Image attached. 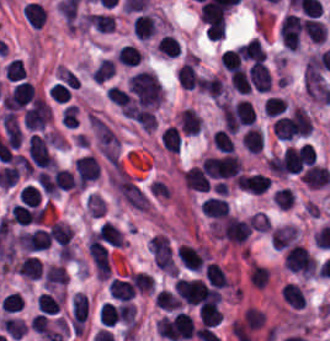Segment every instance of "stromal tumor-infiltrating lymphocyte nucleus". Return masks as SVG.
Masks as SVG:
<instances>
[{
	"label": "stromal tumor-infiltrating lymphocyte nucleus",
	"instance_id": "stromal-tumor-infiltrating-lymphocyte-nucleus-1",
	"mask_svg": "<svg viewBox=\"0 0 330 341\" xmlns=\"http://www.w3.org/2000/svg\"><path fill=\"white\" fill-rule=\"evenodd\" d=\"M284 266L293 273L310 277L316 273V261L304 245L293 244L284 253Z\"/></svg>",
	"mask_w": 330,
	"mask_h": 341
},
{
	"label": "stromal tumor-infiltrating lymphocyte nucleus",
	"instance_id": "stromal-tumor-infiltrating-lymphocyte-nucleus-2",
	"mask_svg": "<svg viewBox=\"0 0 330 341\" xmlns=\"http://www.w3.org/2000/svg\"><path fill=\"white\" fill-rule=\"evenodd\" d=\"M173 289L185 305H199L207 297V287L200 279L178 278Z\"/></svg>",
	"mask_w": 330,
	"mask_h": 341
},
{
	"label": "stromal tumor-infiltrating lymphocyte nucleus",
	"instance_id": "stromal-tumor-infiltrating-lymphocyte-nucleus-3",
	"mask_svg": "<svg viewBox=\"0 0 330 341\" xmlns=\"http://www.w3.org/2000/svg\"><path fill=\"white\" fill-rule=\"evenodd\" d=\"M35 98L33 85L30 81L20 80L3 97L2 105L7 110H19Z\"/></svg>",
	"mask_w": 330,
	"mask_h": 341
},
{
	"label": "stromal tumor-infiltrating lymphocyte nucleus",
	"instance_id": "stromal-tumor-infiltrating-lymphocyte-nucleus-4",
	"mask_svg": "<svg viewBox=\"0 0 330 341\" xmlns=\"http://www.w3.org/2000/svg\"><path fill=\"white\" fill-rule=\"evenodd\" d=\"M236 184L248 193L263 194L270 185V178L262 172L245 173L236 177Z\"/></svg>",
	"mask_w": 330,
	"mask_h": 341
},
{
	"label": "stromal tumor-infiltrating lymphocyte nucleus",
	"instance_id": "stromal-tumor-infiltrating-lymphocyte-nucleus-5",
	"mask_svg": "<svg viewBox=\"0 0 330 341\" xmlns=\"http://www.w3.org/2000/svg\"><path fill=\"white\" fill-rule=\"evenodd\" d=\"M183 182L187 189L199 192H209L211 186L209 176L199 166H192L183 172Z\"/></svg>",
	"mask_w": 330,
	"mask_h": 341
},
{
	"label": "stromal tumor-infiltrating lymphocyte nucleus",
	"instance_id": "stromal-tumor-infiltrating-lymphocyte-nucleus-6",
	"mask_svg": "<svg viewBox=\"0 0 330 341\" xmlns=\"http://www.w3.org/2000/svg\"><path fill=\"white\" fill-rule=\"evenodd\" d=\"M246 75L250 87L256 92H269L270 76L263 64L252 62Z\"/></svg>",
	"mask_w": 330,
	"mask_h": 341
},
{
	"label": "stromal tumor-infiltrating lymphocyte nucleus",
	"instance_id": "stromal-tumor-infiltrating-lymphocyte-nucleus-7",
	"mask_svg": "<svg viewBox=\"0 0 330 341\" xmlns=\"http://www.w3.org/2000/svg\"><path fill=\"white\" fill-rule=\"evenodd\" d=\"M200 321L206 327H216L221 324L223 312L219 299H211L199 308Z\"/></svg>",
	"mask_w": 330,
	"mask_h": 341
},
{
	"label": "stromal tumor-infiltrating lymphocyte nucleus",
	"instance_id": "stromal-tumor-infiltrating-lymphocyte-nucleus-8",
	"mask_svg": "<svg viewBox=\"0 0 330 341\" xmlns=\"http://www.w3.org/2000/svg\"><path fill=\"white\" fill-rule=\"evenodd\" d=\"M301 181L309 188H322L330 184V173L325 167L314 163L303 172Z\"/></svg>",
	"mask_w": 330,
	"mask_h": 341
},
{
	"label": "stromal tumor-infiltrating lymphocyte nucleus",
	"instance_id": "stromal-tumor-infiltrating-lymphocyte-nucleus-9",
	"mask_svg": "<svg viewBox=\"0 0 330 341\" xmlns=\"http://www.w3.org/2000/svg\"><path fill=\"white\" fill-rule=\"evenodd\" d=\"M230 207L221 197H208L200 204V211L206 218L226 219Z\"/></svg>",
	"mask_w": 330,
	"mask_h": 341
},
{
	"label": "stromal tumor-infiltrating lymphocyte nucleus",
	"instance_id": "stromal-tumor-infiltrating-lymphocyte-nucleus-10",
	"mask_svg": "<svg viewBox=\"0 0 330 341\" xmlns=\"http://www.w3.org/2000/svg\"><path fill=\"white\" fill-rule=\"evenodd\" d=\"M179 86L193 90L198 82L197 66L194 59H187L179 67L176 75Z\"/></svg>",
	"mask_w": 330,
	"mask_h": 341
},
{
	"label": "stromal tumor-infiltrating lymphocyte nucleus",
	"instance_id": "stromal-tumor-infiltrating-lymphocyte-nucleus-11",
	"mask_svg": "<svg viewBox=\"0 0 330 341\" xmlns=\"http://www.w3.org/2000/svg\"><path fill=\"white\" fill-rule=\"evenodd\" d=\"M15 268L20 276L29 280H37L43 274V263L35 255H27Z\"/></svg>",
	"mask_w": 330,
	"mask_h": 341
},
{
	"label": "stromal tumor-infiltrating lymphocyte nucleus",
	"instance_id": "stromal-tumor-infiltrating-lymphocyte-nucleus-12",
	"mask_svg": "<svg viewBox=\"0 0 330 341\" xmlns=\"http://www.w3.org/2000/svg\"><path fill=\"white\" fill-rule=\"evenodd\" d=\"M237 48L245 61L264 63L267 57L260 40L256 36Z\"/></svg>",
	"mask_w": 330,
	"mask_h": 341
},
{
	"label": "stromal tumor-infiltrating lymphocyte nucleus",
	"instance_id": "stromal-tumor-infiltrating-lymphocyte-nucleus-13",
	"mask_svg": "<svg viewBox=\"0 0 330 341\" xmlns=\"http://www.w3.org/2000/svg\"><path fill=\"white\" fill-rule=\"evenodd\" d=\"M131 30L141 39H149L156 35V18L151 13L137 15L131 26Z\"/></svg>",
	"mask_w": 330,
	"mask_h": 341
},
{
	"label": "stromal tumor-infiltrating lymphocyte nucleus",
	"instance_id": "stromal-tumor-infiltrating-lymphocyte-nucleus-14",
	"mask_svg": "<svg viewBox=\"0 0 330 341\" xmlns=\"http://www.w3.org/2000/svg\"><path fill=\"white\" fill-rule=\"evenodd\" d=\"M264 145L262 130L247 128L241 135V146L247 153L259 154Z\"/></svg>",
	"mask_w": 330,
	"mask_h": 341
},
{
	"label": "stromal tumor-infiltrating lymphocyte nucleus",
	"instance_id": "stromal-tumor-infiltrating-lymphocyte-nucleus-15",
	"mask_svg": "<svg viewBox=\"0 0 330 341\" xmlns=\"http://www.w3.org/2000/svg\"><path fill=\"white\" fill-rule=\"evenodd\" d=\"M178 122L185 135H198L201 129L199 114L189 107L179 113Z\"/></svg>",
	"mask_w": 330,
	"mask_h": 341
},
{
	"label": "stromal tumor-infiltrating lymphocyte nucleus",
	"instance_id": "stromal-tumor-infiltrating-lymphocyte-nucleus-16",
	"mask_svg": "<svg viewBox=\"0 0 330 341\" xmlns=\"http://www.w3.org/2000/svg\"><path fill=\"white\" fill-rule=\"evenodd\" d=\"M205 277L211 287L225 289L231 287V279L226 272L215 263H208L205 266Z\"/></svg>",
	"mask_w": 330,
	"mask_h": 341
},
{
	"label": "stromal tumor-infiltrating lymphocyte nucleus",
	"instance_id": "stromal-tumor-infiltrating-lymphocyte-nucleus-17",
	"mask_svg": "<svg viewBox=\"0 0 330 341\" xmlns=\"http://www.w3.org/2000/svg\"><path fill=\"white\" fill-rule=\"evenodd\" d=\"M280 297L290 308L304 309L306 305L304 292L294 283H287L283 286Z\"/></svg>",
	"mask_w": 330,
	"mask_h": 341
},
{
	"label": "stromal tumor-infiltrating lymphocyte nucleus",
	"instance_id": "stromal-tumor-infiltrating-lymphocyte-nucleus-18",
	"mask_svg": "<svg viewBox=\"0 0 330 341\" xmlns=\"http://www.w3.org/2000/svg\"><path fill=\"white\" fill-rule=\"evenodd\" d=\"M72 327H82L88 317V302L79 292L71 299Z\"/></svg>",
	"mask_w": 330,
	"mask_h": 341
},
{
	"label": "stromal tumor-infiltrating lymphocyte nucleus",
	"instance_id": "stromal-tumor-infiltrating-lymphocyte-nucleus-19",
	"mask_svg": "<svg viewBox=\"0 0 330 341\" xmlns=\"http://www.w3.org/2000/svg\"><path fill=\"white\" fill-rule=\"evenodd\" d=\"M3 127L8 146L17 150L22 134L19 123L12 113H5L3 117Z\"/></svg>",
	"mask_w": 330,
	"mask_h": 341
},
{
	"label": "stromal tumor-infiltrating lymphocyte nucleus",
	"instance_id": "stromal-tumor-infiltrating-lymphocyte-nucleus-20",
	"mask_svg": "<svg viewBox=\"0 0 330 341\" xmlns=\"http://www.w3.org/2000/svg\"><path fill=\"white\" fill-rule=\"evenodd\" d=\"M85 25L108 34L115 30L114 17L107 14L88 13Z\"/></svg>",
	"mask_w": 330,
	"mask_h": 341
},
{
	"label": "stromal tumor-infiltrating lymphocyte nucleus",
	"instance_id": "stromal-tumor-infiltrating-lymphocyte-nucleus-21",
	"mask_svg": "<svg viewBox=\"0 0 330 341\" xmlns=\"http://www.w3.org/2000/svg\"><path fill=\"white\" fill-rule=\"evenodd\" d=\"M109 292L113 299L128 301L132 299L135 291L125 279L111 278Z\"/></svg>",
	"mask_w": 330,
	"mask_h": 341
},
{
	"label": "stromal tumor-infiltrating lymphocyte nucleus",
	"instance_id": "stromal-tumor-infiltrating-lymphocyte-nucleus-22",
	"mask_svg": "<svg viewBox=\"0 0 330 341\" xmlns=\"http://www.w3.org/2000/svg\"><path fill=\"white\" fill-rule=\"evenodd\" d=\"M121 314L122 308L105 302L98 310L99 323L111 327L121 320Z\"/></svg>",
	"mask_w": 330,
	"mask_h": 341
},
{
	"label": "stromal tumor-infiltrating lymphocyte nucleus",
	"instance_id": "stromal-tumor-infiltrating-lymphocyte-nucleus-23",
	"mask_svg": "<svg viewBox=\"0 0 330 341\" xmlns=\"http://www.w3.org/2000/svg\"><path fill=\"white\" fill-rule=\"evenodd\" d=\"M181 141L182 137L178 126L168 125L161 136V144L164 150L178 153Z\"/></svg>",
	"mask_w": 330,
	"mask_h": 341
},
{
	"label": "stromal tumor-infiltrating lymphocyte nucleus",
	"instance_id": "stromal-tumor-infiltrating-lymphocyte-nucleus-24",
	"mask_svg": "<svg viewBox=\"0 0 330 341\" xmlns=\"http://www.w3.org/2000/svg\"><path fill=\"white\" fill-rule=\"evenodd\" d=\"M141 52L137 46L125 44L120 48L115 58L126 66H137L141 60Z\"/></svg>",
	"mask_w": 330,
	"mask_h": 341
},
{
	"label": "stromal tumor-infiltrating lymphocyte nucleus",
	"instance_id": "stromal-tumor-infiltrating-lymphocyte-nucleus-25",
	"mask_svg": "<svg viewBox=\"0 0 330 341\" xmlns=\"http://www.w3.org/2000/svg\"><path fill=\"white\" fill-rule=\"evenodd\" d=\"M61 296L41 293L37 309L40 313L54 315L59 313Z\"/></svg>",
	"mask_w": 330,
	"mask_h": 341
},
{
	"label": "stromal tumor-infiltrating lymphocyte nucleus",
	"instance_id": "stromal-tumor-infiltrating-lymphocyte-nucleus-26",
	"mask_svg": "<svg viewBox=\"0 0 330 341\" xmlns=\"http://www.w3.org/2000/svg\"><path fill=\"white\" fill-rule=\"evenodd\" d=\"M129 283L139 293H152L154 282L146 272H132Z\"/></svg>",
	"mask_w": 330,
	"mask_h": 341
},
{
	"label": "stromal tumor-infiltrating lymphocyte nucleus",
	"instance_id": "stromal-tumor-infiltrating-lymphocyte-nucleus-27",
	"mask_svg": "<svg viewBox=\"0 0 330 341\" xmlns=\"http://www.w3.org/2000/svg\"><path fill=\"white\" fill-rule=\"evenodd\" d=\"M115 64L109 59L102 58L92 71V78L95 83H103L112 77Z\"/></svg>",
	"mask_w": 330,
	"mask_h": 341
},
{
	"label": "stromal tumor-infiltrating lymphocyte nucleus",
	"instance_id": "stromal-tumor-infiltrating-lymphocyte-nucleus-28",
	"mask_svg": "<svg viewBox=\"0 0 330 341\" xmlns=\"http://www.w3.org/2000/svg\"><path fill=\"white\" fill-rule=\"evenodd\" d=\"M181 299L178 298L175 294L170 292L168 289H161L156 294L155 305L161 308L162 310H175L179 308Z\"/></svg>",
	"mask_w": 330,
	"mask_h": 341
},
{
	"label": "stromal tumor-infiltrating lymphocyte nucleus",
	"instance_id": "stromal-tumor-infiltrating-lymphocyte-nucleus-29",
	"mask_svg": "<svg viewBox=\"0 0 330 341\" xmlns=\"http://www.w3.org/2000/svg\"><path fill=\"white\" fill-rule=\"evenodd\" d=\"M157 52L167 57H177L179 55V41L172 34H164L157 44Z\"/></svg>",
	"mask_w": 330,
	"mask_h": 341
},
{
	"label": "stromal tumor-infiltrating lymphocyte nucleus",
	"instance_id": "stromal-tumor-infiltrating-lymphocyte-nucleus-30",
	"mask_svg": "<svg viewBox=\"0 0 330 341\" xmlns=\"http://www.w3.org/2000/svg\"><path fill=\"white\" fill-rule=\"evenodd\" d=\"M270 277V271L268 267L253 263L251 264L248 279L256 288H263Z\"/></svg>",
	"mask_w": 330,
	"mask_h": 341
},
{
	"label": "stromal tumor-infiltrating lymphocyte nucleus",
	"instance_id": "stromal-tumor-infiltrating-lymphocyte-nucleus-31",
	"mask_svg": "<svg viewBox=\"0 0 330 341\" xmlns=\"http://www.w3.org/2000/svg\"><path fill=\"white\" fill-rule=\"evenodd\" d=\"M214 146L221 152H235L233 139L225 129L215 131Z\"/></svg>",
	"mask_w": 330,
	"mask_h": 341
},
{
	"label": "stromal tumor-infiltrating lymphocyte nucleus",
	"instance_id": "stromal-tumor-infiltrating-lymphocyte-nucleus-32",
	"mask_svg": "<svg viewBox=\"0 0 330 341\" xmlns=\"http://www.w3.org/2000/svg\"><path fill=\"white\" fill-rule=\"evenodd\" d=\"M26 71L20 61V59H13L4 67V77L9 82H16L24 77Z\"/></svg>",
	"mask_w": 330,
	"mask_h": 341
},
{
	"label": "stromal tumor-infiltrating lymphocyte nucleus",
	"instance_id": "stromal-tumor-infiltrating-lymphocyte-nucleus-33",
	"mask_svg": "<svg viewBox=\"0 0 330 341\" xmlns=\"http://www.w3.org/2000/svg\"><path fill=\"white\" fill-rule=\"evenodd\" d=\"M23 302V298L17 292H10L3 297L0 303V309L3 313H16Z\"/></svg>",
	"mask_w": 330,
	"mask_h": 341
},
{
	"label": "stromal tumor-infiltrating lymphocyte nucleus",
	"instance_id": "stromal-tumor-infiltrating-lymphocyte-nucleus-34",
	"mask_svg": "<svg viewBox=\"0 0 330 341\" xmlns=\"http://www.w3.org/2000/svg\"><path fill=\"white\" fill-rule=\"evenodd\" d=\"M230 82L240 95H249L252 90L243 68L230 77Z\"/></svg>",
	"mask_w": 330,
	"mask_h": 341
},
{
	"label": "stromal tumor-infiltrating lymphocyte nucleus",
	"instance_id": "stromal-tumor-infiltrating-lymphocyte-nucleus-35",
	"mask_svg": "<svg viewBox=\"0 0 330 341\" xmlns=\"http://www.w3.org/2000/svg\"><path fill=\"white\" fill-rule=\"evenodd\" d=\"M19 199L26 205L38 206L41 203V193L26 184L19 192Z\"/></svg>",
	"mask_w": 330,
	"mask_h": 341
},
{
	"label": "stromal tumor-infiltrating lymphocyte nucleus",
	"instance_id": "stromal-tumor-infiltrating-lymphocyte-nucleus-36",
	"mask_svg": "<svg viewBox=\"0 0 330 341\" xmlns=\"http://www.w3.org/2000/svg\"><path fill=\"white\" fill-rule=\"evenodd\" d=\"M265 110L267 115H280L286 110L283 97L269 96L265 101Z\"/></svg>",
	"mask_w": 330,
	"mask_h": 341
}]
</instances>
